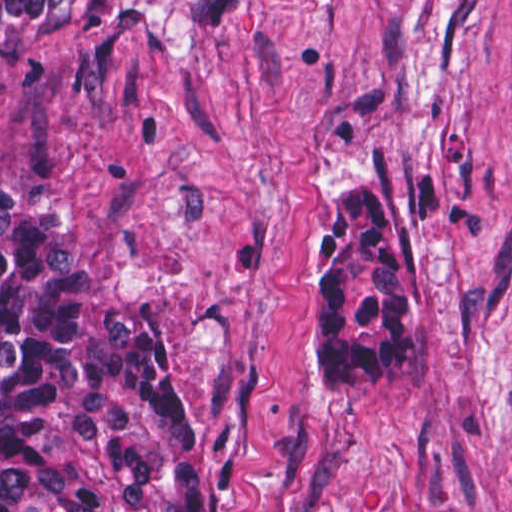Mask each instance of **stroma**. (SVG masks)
<instances>
[{
  "mask_svg": "<svg viewBox=\"0 0 512 512\" xmlns=\"http://www.w3.org/2000/svg\"><path fill=\"white\" fill-rule=\"evenodd\" d=\"M0 175L164 318L205 425L195 512H512V0L69 25L0 69ZM335 178L389 188L427 332L328 396L304 292Z\"/></svg>",
  "mask_w": 512,
  "mask_h": 512,
  "instance_id": "1",
  "label": "stroma"
}]
</instances>
